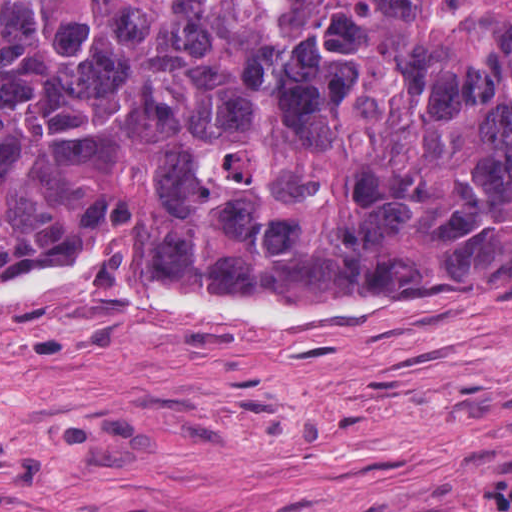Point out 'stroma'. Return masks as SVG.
Instances as JSON below:
<instances>
[{
	"mask_svg": "<svg viewBox=\"0 0 512 512\" xmlns=\"http://www.w3.org/2000/svg\"><path fill=\"white\" fill-rule=\"evenodd\" d=\"M500 480L512 300L228 319L88 276L0 304V512H424Z\"/></svg>",
	"mask_w": 512,
	"mask_h": 512,
	"instance_id": "stroma-1",
	"label": "stroma"
}]
</instances>
